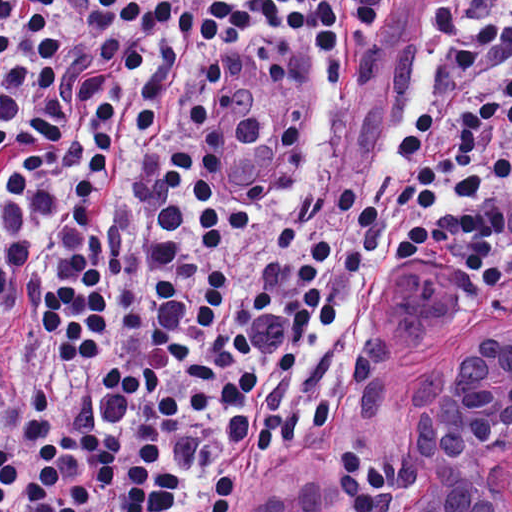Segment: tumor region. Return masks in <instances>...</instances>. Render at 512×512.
<instances>
[{"mask_svg": "<svg viewBox=\"0 0 512 512\" xmlns=\"http://www.w3.org/2000/svg\"><path fill=\"white\" fill-rule=\"evenodd\" d=\"M392 285L393 280L384 293V311L377 319L364 356L350 377L338 422L295 460L281 480L252 498L247 512H314L324 467L353 433L382 428L410 454V391L373 356Z\"/></svg>", "mask_w": 512, "mask_h": 512, "instance_id": "obj_1", "label": "tumor region"}]
</instances>
